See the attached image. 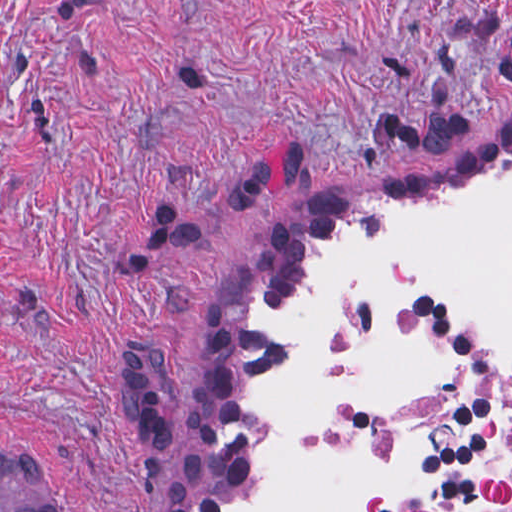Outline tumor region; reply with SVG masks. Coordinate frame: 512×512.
<instances>
[{
	"instance_id": "1",
	"label": "tumor region",
	"mask_w": 512,
	"mask_h": 512,
	"mask_svg": "<svg viewBox=\"0 0 512 512\" xmlns=\"http://www.w3.org/2000/svg\"><path fill=\"white\" fill-rule=\"evenodd\" d=\"M0 512H58L30 456L0 449Z\"/></svg>"
}]
</instances>
